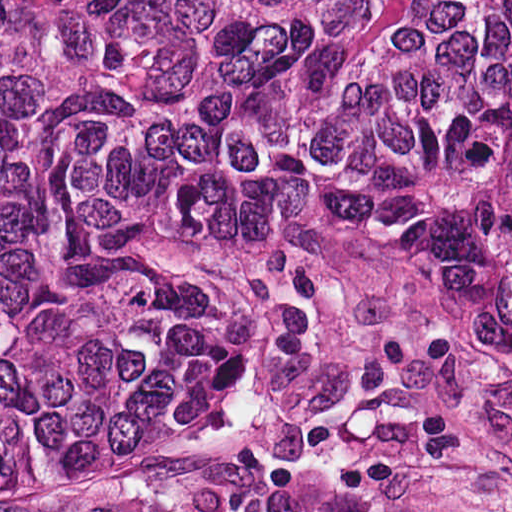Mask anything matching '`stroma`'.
<instances>
[{
	"instance_id": "1",
	"label": "stroma",
	"mask_w": 512,
	"mask_h": 512,
	"mask_svg": "<svg viewBox=\"0 0 512 512\" xmlns=\"http://www.w3.org/2000/svg\"><path fill=\"white\" fill-rule=\"evenodd\" d=\"M214 236L243 310L170 407L0 512H512V354L436 263L298 213Z\"/></svg>"
}]
</instances>
